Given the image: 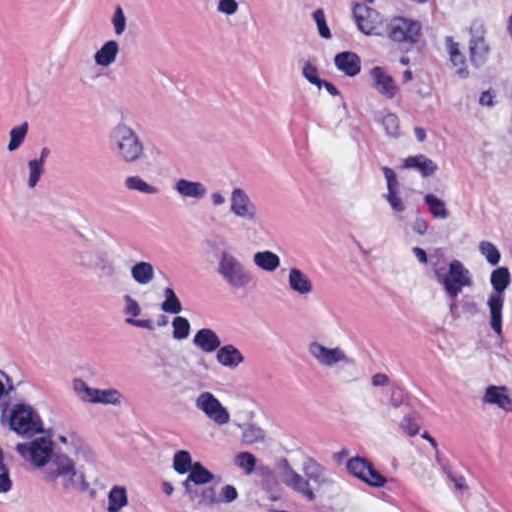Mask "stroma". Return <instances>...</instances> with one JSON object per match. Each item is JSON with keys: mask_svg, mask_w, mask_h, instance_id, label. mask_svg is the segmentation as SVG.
I'll use <instances>...</instances> for the list:
<instances>
[{"mask_svg": "<svg viewBox=\"0 0 512 512\" xmlns=\"http://www.w3.org/2000/svg\"><path fill=\"white\" fill-rule=\"evenodd\" d=\"M511 133L512 0H0V512H512Z\"/></svg>", "mask_w": 512, "mask_h": 512, "instance_id": "35a3bbf8", "label": "stroma"}]
</instances>
